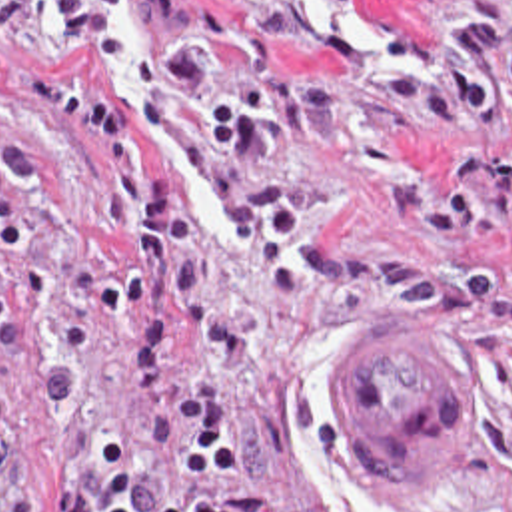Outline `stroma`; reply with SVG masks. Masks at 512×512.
I'll return each instance as SVG.
<instances>
[{"mask_svg": "<svg viewBox=\"0 0 512 512\" xmlns=\"http://www.w3.org/2000/svg\"><path fill=\"white\" fill-rule=\"evenodd\" d=\"M89 1L119 41L19 7L15 51L109 83L197 221L253 357L223 363L191 319L169 384L221 412L253 512H512V0H339L377 53L319 37L299 0ZM123 237L121 189L0 87V512H55L103 442L149 454L123 323L97 307ZM411 317L481 364L455 494L385 488L329 398L363 329Z\"/></svg>", "mask_w": 512, "mask_h": 512, "instance_id": "stroma-1", "label": "stroma"}]
</instances>
